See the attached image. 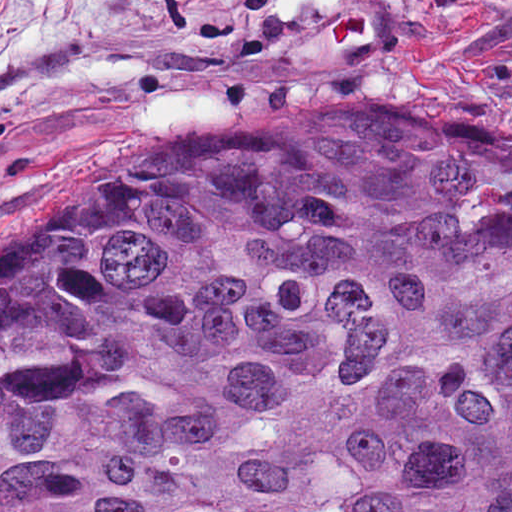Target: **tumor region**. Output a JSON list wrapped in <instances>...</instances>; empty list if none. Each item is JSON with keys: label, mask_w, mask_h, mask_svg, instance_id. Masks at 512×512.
Segmentation results:
<instances>
[{"label": "tumor region", "mask_w": 512, "mask_h": 512, "mask_svg": "<svg viewBox=\"0 0 512 512\" xmlns=\"http://www.w3.org/2000/svg\"><path fill=\"white\" fill-rule=\"evenodd\" d=\"M292 100L0 280V512H512V145Z\"/></svg>", "instance_id": "e687c5a6"}]
</instances>
